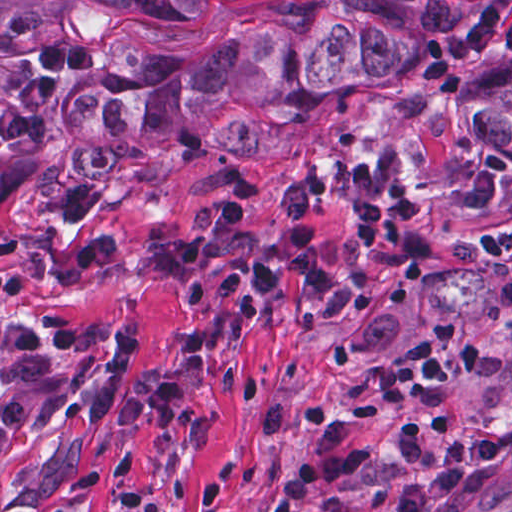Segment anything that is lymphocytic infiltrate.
Returning <instances> with one entry per match:
<instances>
[{"instance_id": "lymphocytic-infiltrate-1", "label": "lymphocytic infiltrate", "mask_w": 512, "mask_h": 512, "mask_svg": "<svg viewBox=\"0 0 512 512\" xmlns=\"http://www.w3.org/2000/svg\"><path fill=\"white\" fill-rule=\"evenodd\" d=\"M503 35L512 54V8L507 0H489L465 28L434 42L422 58L419 74L442 96L461 93L460 72L475 66ZM102 67V48L90 43L37 46L32 63L0 47V152L29 150L61 132L71 109L75 86ZM326 182L315 175L282 186L276 193L278 224L265 250L240 237L251 195L246 172L231 174L213 197L189 204L183 238L143 252L134 263L140 279L167 287L179 301L204 296L202 270L207 258L223 269L211 288L226 312L263 311L248 291L275 289L284 281L292 311L307 319H334L352 313L361 287L333 266L315 235L313 210ZM98 187L91 179L73 186L60 201V221L75 231L76 246L56 271L59 284H78L94 275L117 251V242L91 226ZM360 264L372 272H417L437 247L430 231L433 192L417 183H400L354 211ZM483 249L501 271V297L512 305V231L483 237ZM31 295L27 278L0 268V303ZM483 364V344L455 315L434 324L422 353L397 364L389 382L347 407L340 415L325 403L305 404L313 434L310 449L296 470L275 491V512H301L305 498L322 486L339 484L363 468L369 452L350 433L355 424L378 426L397 413L404 427L395 451L399 460L427 466L439 456L434 435L449 433L459 411L451 403L431 400ZM15 370L14 385L0 406L6 433H22L34 417L51 414L71 398V381L57 363V352L42 330L0 319V367ZM512 444V408L498 430L453 440L439 469L405 488L393 512H421L445 496L471 494L484 486ZM3 502L0 498V510Z\"/></svg>"}]
</instances>
